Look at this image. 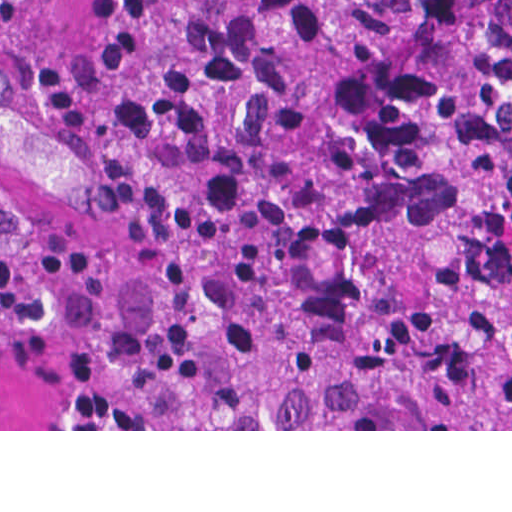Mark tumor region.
<instances>
[{
    "label": "tumor region",
    "mask_w": 512,
    "mask_h": 512,
    "mask_svg": "<svg viewBox=\"0 0 512 512\" xmlns=\"http://www.w3.org/2000/svg\"><path fill=\"white\" fill-rule=\"evenodd\" d=\"M90 65L145 193L95 346L134 408L512 429V0H90Z\"/></svg>",
    "instance_id": "e687c5a6"
}]
</instances>
